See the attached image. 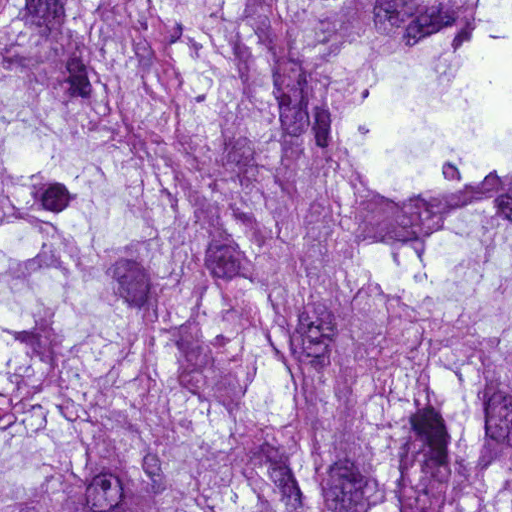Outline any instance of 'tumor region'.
Here are the masks:
<instances>
[{"label": "tumor region", "mask_w": 512, "mask_h": 512, "mask_svg": "<svg viewBox=\"0 0 512 512\" xmlns=\"http://www.w3.org/2000/svg\"><path fill=\"white\" fill-rule=\"evenodd\" d=\"M1 512H512V0H1Z\"/></svg>", "instance_id": "tumor-region-1"}]
</instances>
